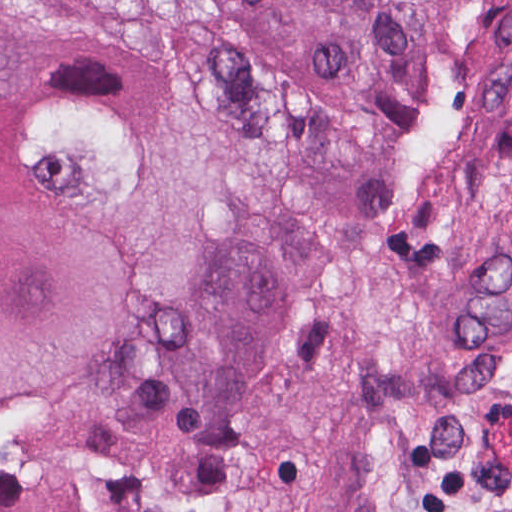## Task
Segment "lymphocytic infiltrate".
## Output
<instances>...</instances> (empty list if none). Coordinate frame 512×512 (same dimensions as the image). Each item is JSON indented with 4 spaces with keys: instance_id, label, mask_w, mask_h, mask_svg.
<instances>
[{
    "instance_id": "lymphocytic-infiltrate-1",
    "label": "lymphocytic infiltrate",
    "mask_w": 512,
    "mask_h": 512,
    "mask_svg": "<svg viewBox=\"0 0 512 512\" xmlns=\"http://www.w3.org/2000/svg\"><path fill=\"white\" fill-rule=\"evenodd\" d=\"M399 512H495V509L475 475L413 489Z\"/></svg>"
}]
</instances>
